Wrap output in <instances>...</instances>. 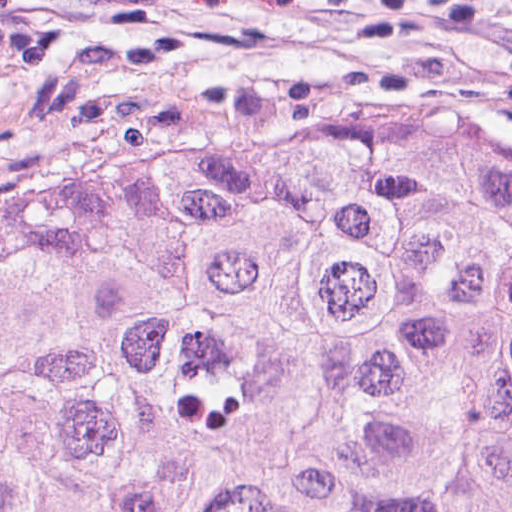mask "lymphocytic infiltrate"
I'll list each match as a JSON object with an SVG mask.
<instances>
[{
	"label": "lymphocytic infiltrate",
	"mask_w": 512,
	"mask_h": 512,
	"mask_svg": "<svg viewBox=\"0 0 512 512\" xmlns=\"http://www.w3.org/2000/svg\"><path fill=\"white\" fill-rule=\"evenodd\" d=\"M392 19L437 28L460 38L512 50V41L470 24L450 0H385Z\"/></svg>",
	"instance_id": "1"
}]
</instances>
